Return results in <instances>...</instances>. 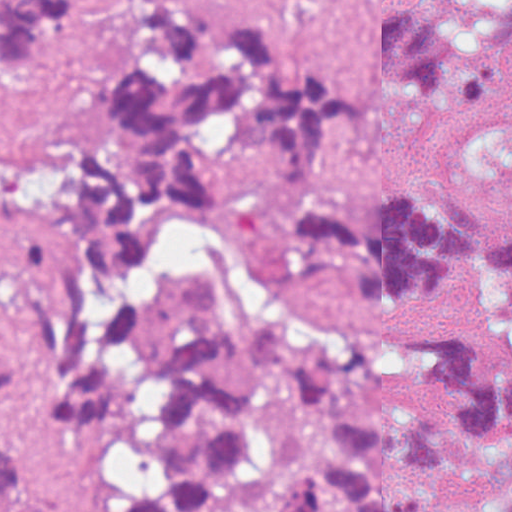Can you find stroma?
I'll list each match as a JSON object with an SVG mask.
<instances>
[{"instance_id": "obj_1", "label": "stroma", "mask_w": 512, "mask_h": 512, "mask_svg": "<svg viewBox=\"0 0 512 512\" xmlns=\"http://www.w3.org/2000/svg\"><path fill=\"white\" fill-rule=\"evenodd\" d=\"M445 0H296L307 44L363 81L365 125L351 161L333 171V199L374 205L393 187L453 181L482 221H512V27L494 83L480 103L433 107L393 95L366 55L370 9H440ZM113 32L100 20L57 64L69 76L107 78ZM71 85L50 74L0 78V255L34 248L42 234L30 180L81 113ZM206 259L234 313L286 312L283 344L313 359L358 346L383 324L419 318L377 301L348 277L302 254L292 220L259 167L245 165L237 204L179 224L171 258L144 272L130 306L149 346L165 349L189 331L180 282ZM467 337L483 366L512 369V260L474 280L443 317ZM65 385H30L0 405V450L16 460L19 493L0 512H123L158 479L157 409L152 381L102 425H64L54 396Z\"/></svg>"}]
</instances>
